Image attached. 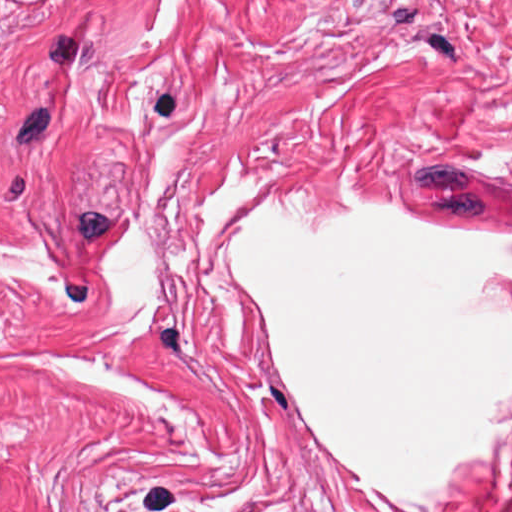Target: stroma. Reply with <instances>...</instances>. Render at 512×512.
Returning a JSON list of instances; mask_svg holds the SVG:
<instances>
[{"mask_svg": "<svg viewBox=\"0 0 512 512\" xmlns=\"http://www.w3.org/2000/svg\"><path fill=\"white\" fill-rule=\"evenodd\" d=\"M274 193L512 237V0H0V512H394L235 300ZM450 512H512V390Z\"/></svg>", "mask_w": 512, "mask_h": 512, "instance_id": "stroma-1", "label": "stroma"}]
</instances>
